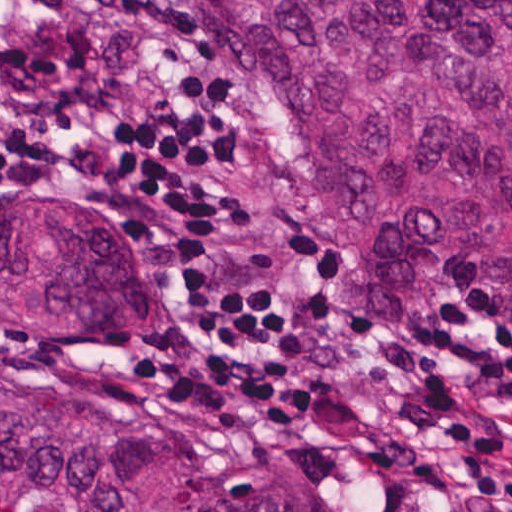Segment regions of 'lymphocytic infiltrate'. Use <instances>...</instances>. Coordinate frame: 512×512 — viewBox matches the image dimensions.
<instances>
[{
	"instance_id": "lymphocytic-infiltrate-1",
	"label": "lymphocytic infiltrate",
	"mask_w": 512,
	"mask_h": 512,
	"mask_svg": "<svg viewBox=\"0 0 512 512\" xmlns=\"http://www.w3.org/2000/svg\"><path fill=\"white\" fill-rule=\"evenodd\" d=\"M0 175L127 213L192 298L175 343L138 363L149 397L249 395L321 342L304 254L252 224L241 136L219 81L182 67L150 0H0ZM409 394L405 422L368 432L367 462L433 502L454 497L425 436L469 483L463 512H512V272L433 318L409 348L375 346Z\"/></svg>"
}]
</instances>
